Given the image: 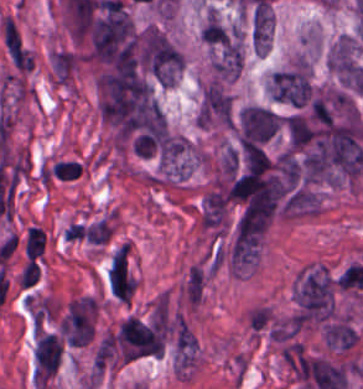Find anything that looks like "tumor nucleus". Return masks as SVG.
I'll return each mask as SVG.
<instances>
[{
    "instance_id": "tumor-nucleus-1",
    "label": "tumor nucleus",
    "mask_w": 363,
    "mask_h": 389,
    "mask_svg": "<svg viewBox=\"0 0 363 389\" xmlns=\"http://www.w3.org/2000/svg\"><path fill=\"white\" fill-rule=\"evenodd\" d=\"M266 91L270 98L295 106L311 99L312 86L305 63L297 61L273 72Z\"/></svg>"
},
{
    "instance_id": "tumor-nucleus-2",
    "label": "tumor nucleus",
    "mask_w": 363,
    "mask_h": 389,
    "mask_svg": "<svg viewBox=\"0 0 363 389\" xmlns=\"http://www.w3.org/2000/svg\"><path fill=\"white\" fill-rule=\"evenodd\" d=\"M231 117L227 92L217 82H209L198 107V124H228Z\"/></svg>"
},
{
    "instance_id": "tumor-nucleus-3",
    "label": "tumor nucleus",
    "mask_w": 363,
    "mask_h": 389,
    "mask_svg": "<svg viewBox=\"0 0 363 389\" xmlns=\"http://www.w3.org/2000/svg\"><path fill=\"white\" fill-rule=\"evenodd\" d=\"M325 338L336 351H344L356 343L357 332L352 322L335 317L325 324Z\"/></svg>"
},
{
    "instance_id": "tumor-nucleus-4",
    "label": "tumor nucleus",
    "mask_w": 363,
    "mask_h": 389,
    "mask_svg": "<svg viewBox=\"0 0 363 389\" xmlns=\"http://www.w3.org/2000/svg\"><path fill=\"white\" fill-rule=\"evenodd\" d=\"M289 145L293 150L305 147L312 136V121L307 116L289 115L284 124Z\"/></svg>"
}]
</instances>
